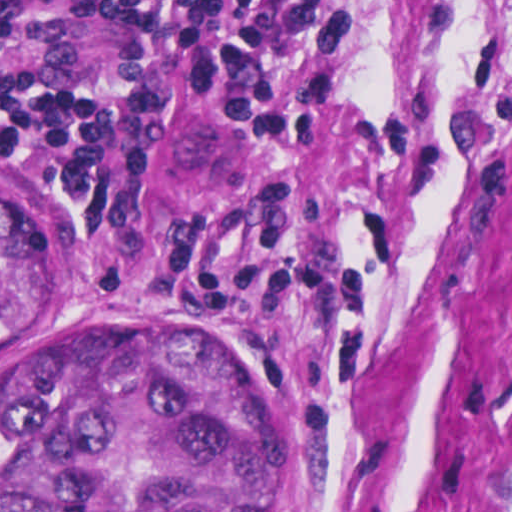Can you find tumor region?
Here are the masks:
<instances>
[{"label":"tumor region","instance_id":"obj_1","mask_svg":"<svg viewBox=\"0 0 512 512\" xmlns=\"http://www.w3.org/2000/svg\"><path fill=\"white\" fill-rule=\"evenodd\" d=\"M52 266L43 203L0 178V354L37 336ZM160 321L0 355V512H293L295 420Z\"/></svg>","mask_w":512,"mask_h":512}]
</instances>
